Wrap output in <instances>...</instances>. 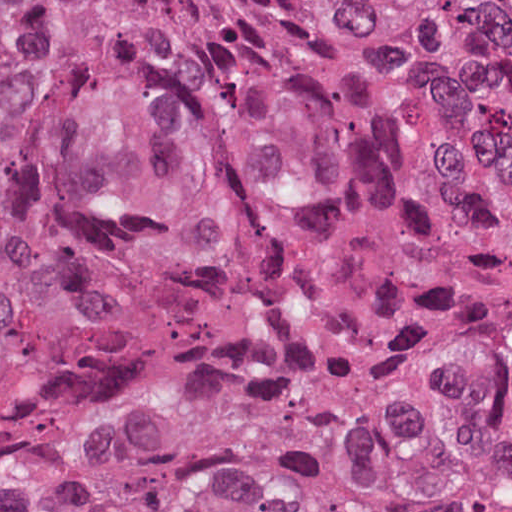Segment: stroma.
I'll use <instances>...</instances> for the list:
<instances>
[{
    "instance_id": "1",
    "label": "stroma",
    "mask_w": 512,
    "mask_h": 512,
    "mask_svg": "<svg viewBox=\"0 0 512 512\" xmlns=\"http://www.w3.org/2000/svg\"><path fill=\"white\" fill-rule=\"evenodd\" d=\"M19 19V221L11 263L0 286V354L11 339L39 273L53 194L56 96L44 52L51 17L92 9L118 25L185 88L223 111L268 154L308 203L314 220L353 263L405 275H512V202L485 214L462 256H396L339 232L314 195L307 174L280 140L245 106L176 54L156 33L102 0H15Z\"/></svg>"
}]
</instances>
